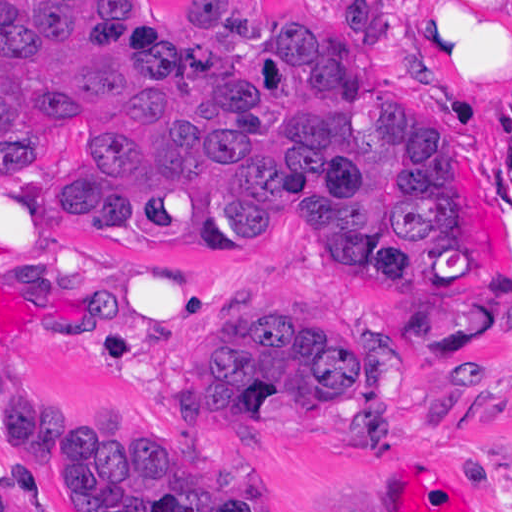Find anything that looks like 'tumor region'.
Wrapping results in <instances>:
<instances>
[{
  "instance_id": "obj_1",
  "label": "tumor region",
  "mask_w": 512,
  "mask_h": 512,
  "mask_svg": "<svg viewBox=\"0 0 512 512\" xmlns=\"http://www.w3.org/2000/svg\"><path fill=\"white\" fill-rule=\"evenodd\" d=\"M340 0H246L208 40L179 0L0 6V172L42 225L151 264L260 247L401 306L474 298V263L411 168L399 77ZM512 103V41L507 48ZM406 360L372 326L335 345L270 314L236 315L197 359L198 409L384 456ZM0 433L71 512H265L260 482H213L167 450L0 387ZM0 512H41L0 463ZM328 512H380L344 498Z\"/></svg>"
}]
</instances>
